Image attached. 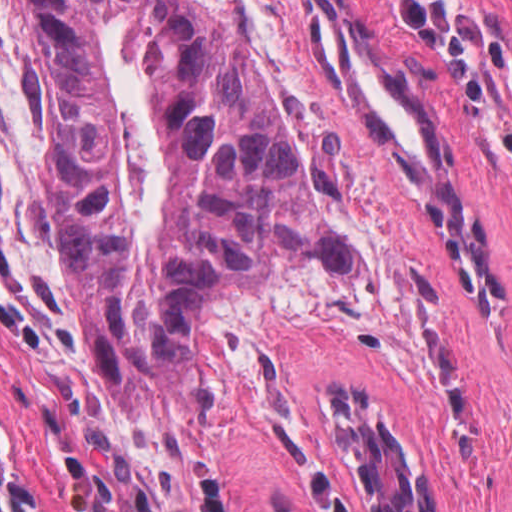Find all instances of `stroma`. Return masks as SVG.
<instances>
[{
    "instance_id": "stroma-1",
    "label": "stroma",
    "mask_w": 512,
    "mask_h": 512,
    "mask_svg": "<svg viewBox=\"0 0 512 512\" xmlns=\"http://www.w3.org/2000/svg\"><path fill=\"white\" fill-rule=\"evenodd\" d=\"M512 342V0H431L492 91L468 113L456 75L386 0H315Z\"/></svg>"
}]
</instances>
